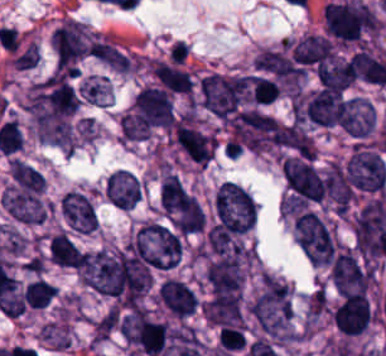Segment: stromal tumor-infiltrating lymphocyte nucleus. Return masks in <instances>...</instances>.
<instances>
[{
    "label": "stromal tumor-infiltrating lymphocyte nucleus",
    "instance_id": "stromal-tumor-infiltrating-lymphocyte-nucleus-1",
    "mask_svg": "<svg viewBox=\"0 0 386 356\" xmlns=\"http://www.w3.org/2000/svg\"><path fill=\"white\" fill-rule=\"evenodd\" d=\"M281 93L277 82L262 76H254L253 102L261 104L272 103Z\"/></svg>",
    "mask_w": 386,
    "mask_h": 356
}]
</instances>
